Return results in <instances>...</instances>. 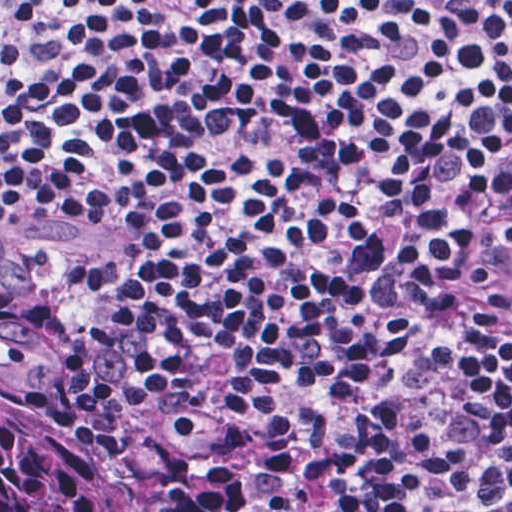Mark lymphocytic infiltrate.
I'll return each mask as SVG.
<instances>
[{
  "label": "lymphocytic infiltrate",
  "instance_id": "lymphocytic-infiltrate-1",
  "mask_svg": "<svg viewBox=\"0 0 512 512\" xmlns=\"http://www.w3.org/2000/svg\"><path fill=\"white\" fill-rule=\"evenodd\" d=\"M0 236L139 512H512V1H0Z\"/></svg>",
  "mask_w": 512,
  "mask_h": 512
}]
</instances>
